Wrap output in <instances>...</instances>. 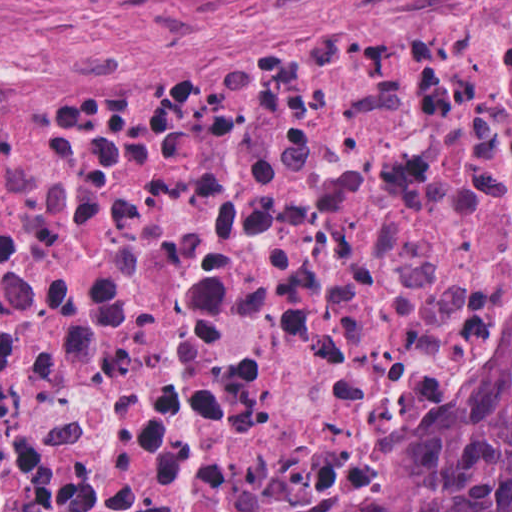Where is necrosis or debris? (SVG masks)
<instances>
[{"mask_svg":"<svg viewBox=\"0 0 512 512\" xmlns=\"http://www.w3.org/2000/svg\"><path fill=\"white\" fill-rule=\"evenodd\" d=\"M512 245V0L176 91L0 89V512H179L371 449Z\"/></svg>","mask_w":512,"mask_h":512,"instance_id":"4bbe7bcc","label":"necrosis or debris"}]
</instances>
